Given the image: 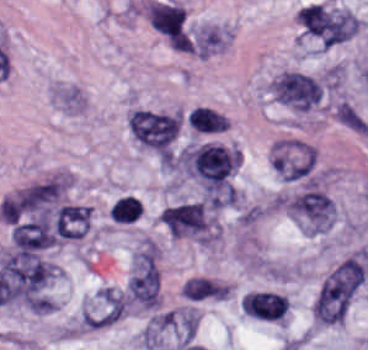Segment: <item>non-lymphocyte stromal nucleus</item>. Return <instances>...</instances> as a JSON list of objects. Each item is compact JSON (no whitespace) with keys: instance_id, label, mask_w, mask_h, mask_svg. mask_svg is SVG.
<instances>
[{"instance_id":"non-lymphocyte-stromal-nucleus-1","label":"non-lymphocyte stromal nucleus","mask_w":368,"mask_h":350,"mask_svg":"<svg viewBox=\"0 0 368 350\" xmlns=\"http://www.w3.org/2000/svg\"><path fill=\"white\" fill-rule=\"evenodd\" d=\"M368 256L356 253L339 263L321 282L314 314H343L362 284Z\"/></svg>"},{"instance_id":"non-lymphocyte-stromal-nucleus-2","label":"non-lymphocyte stromal nucleus","mask_w":368,"mask_h":350,"mask_svg":"<svg viewBox=\"0 0 368 350\" xmlns=\"http://www.w3.org/2000/svg\"><path fill=\"white\" fill-rule=\"evenodd\" d=\"M148 18L151 24L169 38L180 35L184 7L179 5L149 2Z\"/></svg>"},{"instance_id":"non-lymphocyte-stromal-nucleus-3","label":"non-lymphocyte stromal nucleus","mask_w":368,"mask_h":350,"mask_svg":"<svg viewBox=\"0 0 368 350\" xmlns=\"http://www.w3.org/2000/svg\"><path fill=\"white\" fill-rule=\"evenodd\" d=\"M229 293L228 286L210 277L193 276L183 284L182 296L193 300L223 298Z\"/></svg>"},{"instance_id":"non-lymphocyte-stromal-nucleus-4","label":"non-lymphocyte stromal nucleus","mask_w":368,"mask_h":350,"mask_svg":"<svg viewBox=\"0 0 368 350\" xmlns=\"http://www.w3.org/2000/svg\"><path fill=\"white\" fill-rule=\"evenodd\" d=\"M335 117L344 125L357 132H368V121L347 100H340L333 106Z\"/></svg>"}]
</instances>
